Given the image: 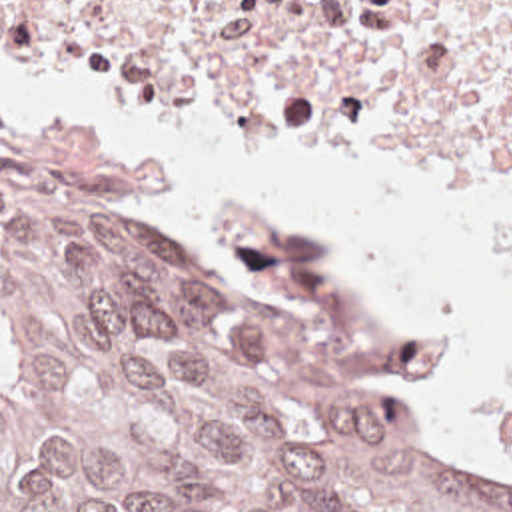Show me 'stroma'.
I'll return each mask as SVG.
<instances>
[{"label":"stroma","instance_id":"stroma-1","mask_svg":"<svg viewBox=\"0 0 512 512\" xmlns=\"http://www.w3.org/2000/svg\"><path fill=\"white\" fill-rule=\"evenodd\" d=\"M0 64L16 68V60L0 48ZM0 122L6 124L18 146L52 180L76 188L90 200L106 204L114 214H144L122 204L124 198H136L154 190L172 170L166 158L148 154H126L100 138L98 126L90 124L78 134H46L32 124L18 126L0 104ZM164 228L186 238L170 220L156 216ZM188 240V238H186ZM333 254V252H331ZM335 256V254H333ZM339 262V260H337ZM341 264V262H339Z\"/></svg>","mask_w":512,"mask_h":512}]
</instances>
